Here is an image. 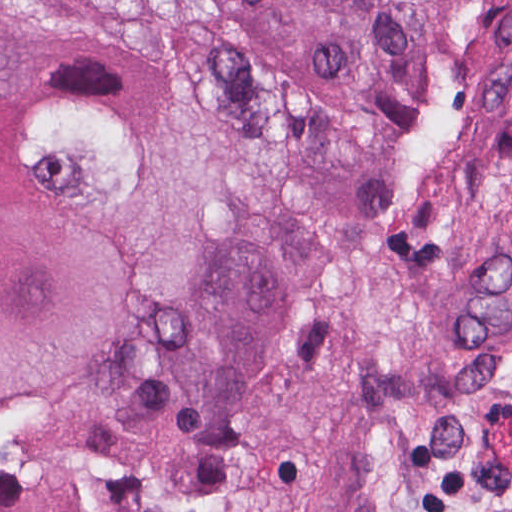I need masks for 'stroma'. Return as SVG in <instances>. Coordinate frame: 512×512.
<instances>
[{
	"label": "stroma",
	"mask_w": 512,
	"mask_h": 512,
	"mask_svg": "<svg viewBox=\"0 0 512 512\" xmlns=\"http://www.w3.org/2000/svg\"><path fill=\"white\" fill-rule=\"evenodd\" d=\"M203 512H399L475 476L512 512V0H469L385 201L223 417Z\"/></svg>",
	"instance_id": "1"
}]
</instances>
